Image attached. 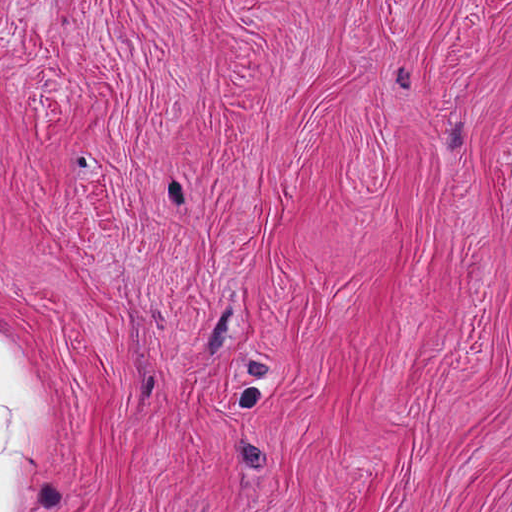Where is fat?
Masks as SVG:
<instances>
[{"label": "fat", "mask_w": 512, "mask_h": 512, "mask_svg": "<svg viewBox=\"0 0 512 512\" xmlns=\"http://www.w3.org/2000/svg\"><path fill=\"white\" fill-rule=\"evenodd\" d=\"M56 459V419L34 376L0 339V512H31Z\"/></svg>", "instance_id": "obj_1"}]
</instances>
